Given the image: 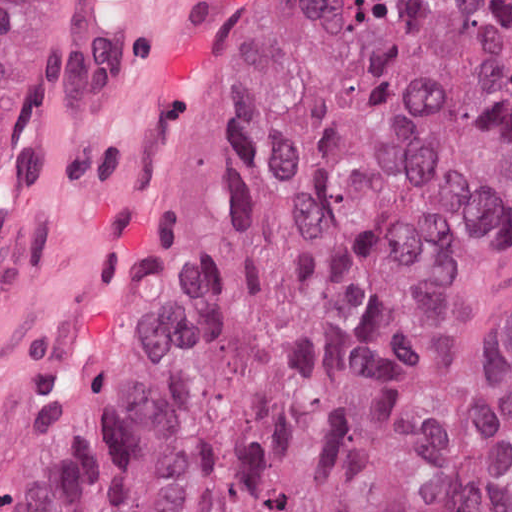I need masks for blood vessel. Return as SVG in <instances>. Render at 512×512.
Listing matches in <instances>:
<instances>
[{
    "mask_svg": "<svg viewBox=\"0 0 512 512\" xmlns=\"http://www.w3.org/2000/svg\"><path fill=\"white\" fill-rule=\"evenodd\" d=\"M252 0H113L0 300V512H29L80 380L178 198Z\"/></svg>",
    "mask_w": 512,
    "mask_h": 512,
    "instance_id": "8fb6f2fc",
    "label": "blood vessel"
}]
</instances>
